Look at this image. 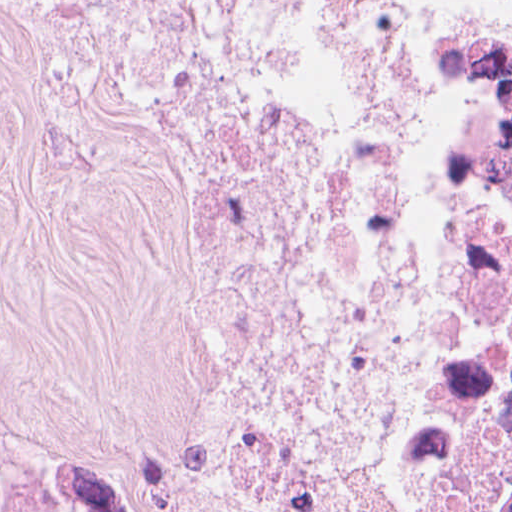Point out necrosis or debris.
I'll return each mask as SVG.
<instances>
[{
  "label": "necrosis or debris",
  "mask_w": 512,
  "mask_h": 512,
  "mask_svg": "<svg viewBox=\"0 0 512 512\" xmlns=\"http://www.w3.org/2000/svg\"><path fill=\"white\" fill-rule=\"evenodd\" d=\"M112 64L193 268L168 433L104 512H323L379 316L384 0H3ZM436 167L339 512H512V0H443ZM0 512H37L0 453Z\"/></svg>",
  "instance_id": "1"
}]
</instances>
